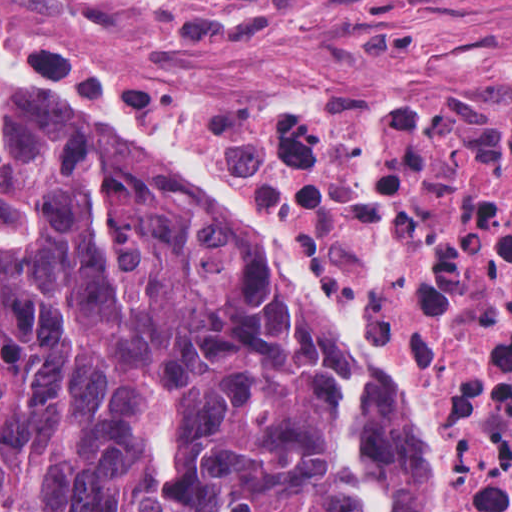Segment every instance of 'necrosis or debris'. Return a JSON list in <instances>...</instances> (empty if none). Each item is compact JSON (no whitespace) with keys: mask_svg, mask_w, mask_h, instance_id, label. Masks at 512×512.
Returning a JSON list of instances; mask_svg holds the SVG:
<instances>
[{"mask_svg":"<svg viewBox=\"0 0 512 512\" xmlns=\"http://www.w3.org/2000/svg\"><path fill=\"white\" fill-rule=\"evenodd\" d=\"M0 32L151 133L374 353L430 373L456 512H512V90L146 88L7 0Z\"/></svg>","mask_w":512,"mask_h":512,"instance_id":"4bbe7bcc","label":"necrosis or debris"}]
</instances>
